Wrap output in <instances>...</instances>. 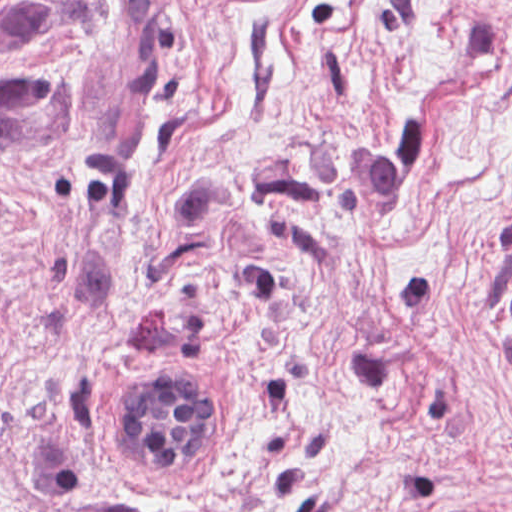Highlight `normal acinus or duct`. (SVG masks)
I'll use <instances>...</instances> for the list:
<instances>
[{
    "label": "normal acinus or duct",
    "mask_w": 512,
    "mask_h": 512,
    "mask_svg": "<svg viewBox=\"0 0 512 512\" xmlns=\"http://www.w3.org/2000/svg\"><path fill=\"white\" fill-rule=\"evenodd\" d=\"M196 381L200 382L170 376L131 379L113 416V450L117 456L190 453L207 424V400Z\"/></svg>",
    "instance_id": "1"
}]
</instances>
